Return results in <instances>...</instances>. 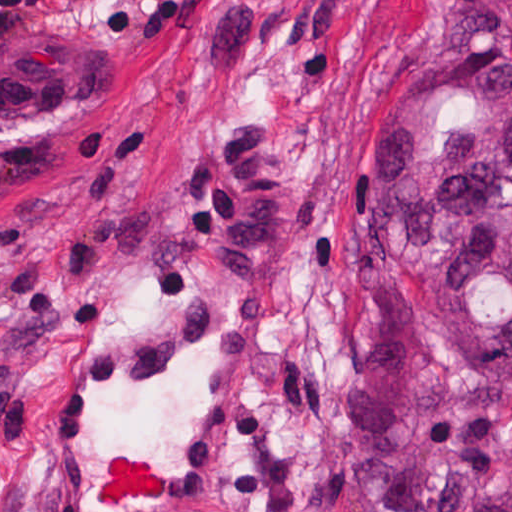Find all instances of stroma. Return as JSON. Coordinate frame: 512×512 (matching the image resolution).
<instances>
[{
	"label": "stroma",
	"mask_w": 512,
	"mask_h": 512,
	"mask_svg": "<svg viewBox=\"0 0 512 512\" xmlns=\"http://www.w3.org/2000/svg\"><path fill=\"white\" fill-rule=\"evenodd\" d=\"M512 0H0V512H46L44 388L168 311L276 357L200 512H379L359 451L354 150L390 68Z\"/></svg>",
	"instance_id": "1"
}]
</instances>
